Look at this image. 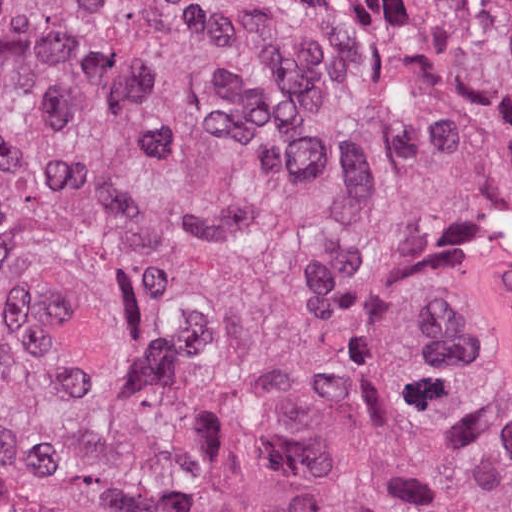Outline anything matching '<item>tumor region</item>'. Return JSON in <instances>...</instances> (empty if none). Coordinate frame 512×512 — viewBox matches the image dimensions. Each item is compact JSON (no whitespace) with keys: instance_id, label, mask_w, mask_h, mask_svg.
<instances>
[{"instance_id":"obj_1","label":"tumor region","mask_w":512,"mask_h":512,"mask_svg":"<svg viewBox=\"0 0 512 512\" xmlns=\"http://www.w3.org/2000/svg\"><path fill=\"white\" fill-rule=\"evenodd\" d=\"M0 512H512V0H0Z\"/></svg>"}]
</instances>
